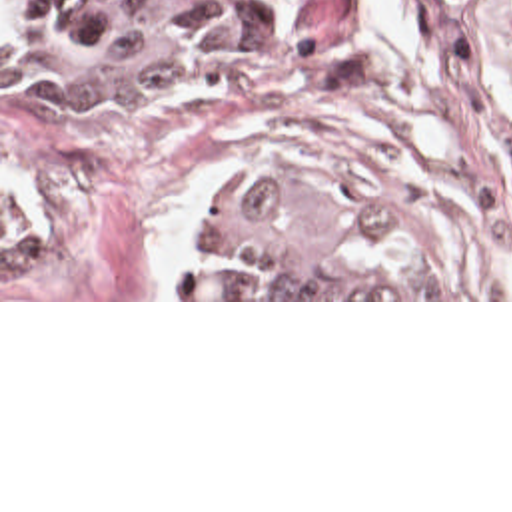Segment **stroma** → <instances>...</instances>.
<instances>
[{
  "label": "stroma",
  "instance_id": "stroma-1",
  "mask_svg": "<svg viewBox=\"0 0 512 512\" xmlns=\"http://www.w3.org/2000/svg\"><path fill=\"white\" fill-rule=\"evenodd\" d=\"M244 66L2 102L0 302H512V0H238ZM391 222L421 298H196L242 178Z\"/></svg>",
  "mask_w": 512,
  "mask_h": 512
}]
</instances>
